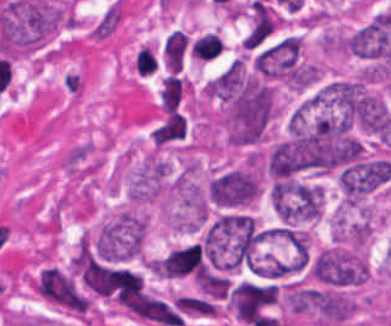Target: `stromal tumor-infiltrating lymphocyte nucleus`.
<instances>
[{
	"mask_svg": "<svg viewBox=\"0 0 391 326\" xmlns=\"http://www.w3.org/2000/svg\"><path fill=\"white\" fill-rule=\"evenodd\" d=\"M189 53V35L175 27L161 45V66L164 72L171 75L181 71Z\"/></svg>",
	"mask_w": 391,
	"mask_h": 326,
	"instance_id": "obj_1",
	"label": "stromal tumor-infiltrating lymphocyte nucleus"
},
{
	"mask_svg": "<svg viewBox=\"0 0 391 326\" xmlns=\"http://www.w3.org/2000/svg\"><path fill=\"white\" fill-rule=\"evenodd\" d=\"M187 125L184 118L177 111H170L155 131V144H165L184 139Z\"/></svg>",
	"mask_w": 391,
	"mask_h": 326,
	"instance_id": "obj_2",
	"label": "stromal tumor-infiltrating lymphocyte nucleus"
},
{
	"mask_svg": "<svg viewBox=\"0 0 391 326\" xmlns=\"http://www.w3.org/2000/svg\"><path fill=\"white\" fill-rule=\"evenodd\" d=\"M184 90V79L177 74L162 78L160 90L161 109L173 110L179 103Z\"/></svg>",
	"mask_w": 391,
	"mask_h": 326,
	"instance_id": "obj_3",
	"label": "stromal tumor-infiltrating lymphocyte nucleus"
},
{
	"mask_svg": "<svg viewBox=\"0 0 391 326\" xmlns=\"http://www.w3.org/2000/svg\"><path fill=\"white\" fill-rule=\"evenodd\" d=\"M223 46L224 45L217 34L213 32H205L193 41L191 57L206 62L216 57Z\"/></svg>",
	"mask_w": 391,
	"mask_h": 326,
	"instance_id": "obj_4",
	"label": "stromal tumor-infiltrating lymphocyte nucleus"
}]
</instances>
